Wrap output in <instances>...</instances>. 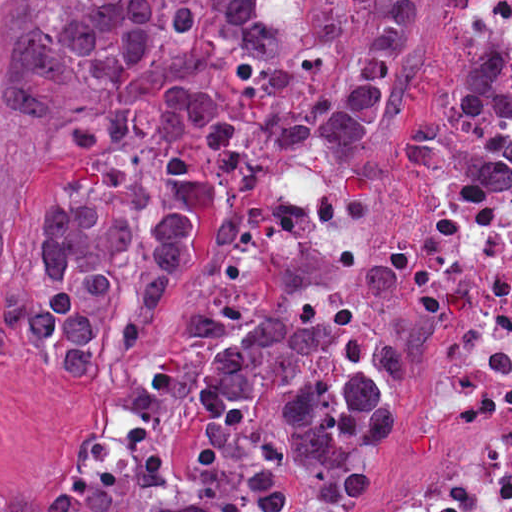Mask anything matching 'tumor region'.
Here are the masks:
<instances>
[{
	"label": "tumor region",
	"instance_id": "1",
	"mask_svg": "<svg viewBox=\"0 0 512 512\" xmlns=\"http://www.w3.org/2000/svg\"><path fill=\"white\" fill-rule=\"evenodd\" d=\"M426 31L417 0H196L0 88L90 156L32 232L0 215V335L89 378L171 322L133 422L0 484V512H300L293 471L334 503L370 493L399 396L344 352L351 320L236 323L190 288L202 251L256 221L269 156L392 126ZM460 54L455 85L398 128L402 176L508 191L507 54L487 38Z\"/></svg>",
	"mask_w": 512,
	"mask_h": 512
}]
</instances>
